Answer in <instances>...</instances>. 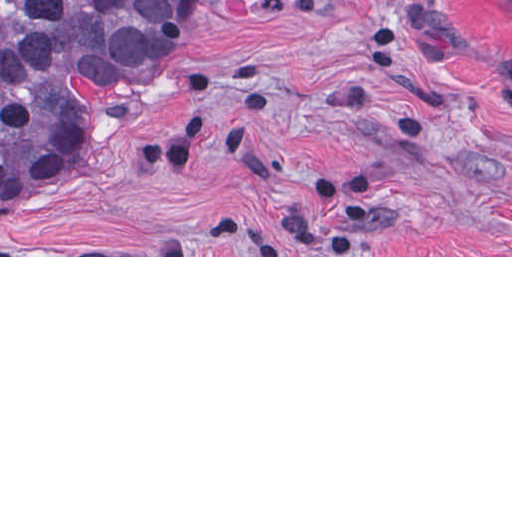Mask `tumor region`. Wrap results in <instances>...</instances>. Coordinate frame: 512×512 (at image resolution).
Masks as SVG:
<instances>
[{
    "label": "tumor region",
    "mask_w": 512,
    "mask_h": 512,
    "mask_svg": "<svg viewBox=\"0 0 512 512\" xmlns=\"http://www.w3.org/2000/svg\"><path fill=\"white\" fill-rule=\"evenodd\" d=\"M209 3L0 0V205L72 186L62 168L89 107L143 84Z\"/></svg>",
    "instance_id": "obj_1"
}]
</instances>
